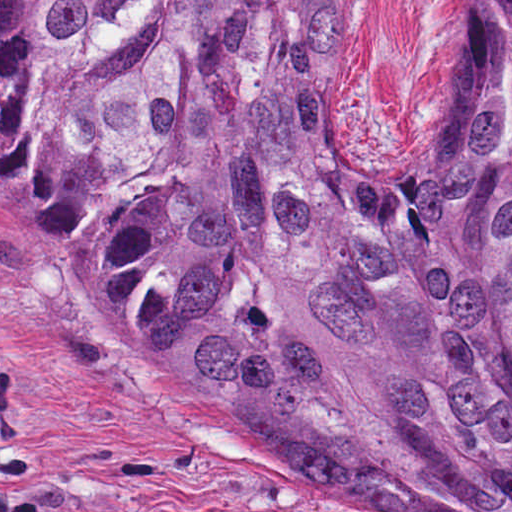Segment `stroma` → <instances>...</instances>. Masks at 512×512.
<instances>
[{
  "mask_svg": "<svg viewBox=\"0 0 512 512\" xmlns=\"http://www.w3.org/2000/svg\"><path fill=\"white\" fill-rule=\"evenodd\" d=\"M464 64V0H357L349 162H417ZM0 512H345L92 303L80 240L0 232Z\"/></svg>",
  "mask_w": 512,
  "mask_h": 512,
  "instance_id": "1",
  "label": "stroma"
}]
</instances>
